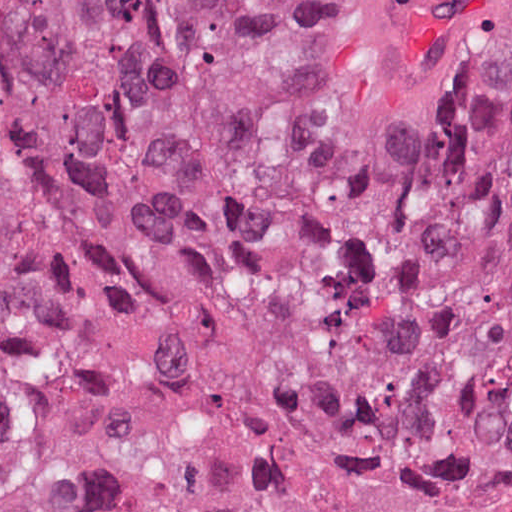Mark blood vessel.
Here are the masks:
<instances>
[{
  "instance_id": "blood-vessel-1",
  "label": "blood vessel",
  "mask_w": 512,
  "mask_h": 512,
  "mask_svg": "<svg viewBox=\"0 0 512 512\" xmlns=\"http://www.w3.org/2000/svg\"><path fill=\"white\" fill-rule=\"evenodd\" d=\"M512 50V0H377L347 71L335 148L371 172L467 109Z\"/></svg>"
}]
</instances>
